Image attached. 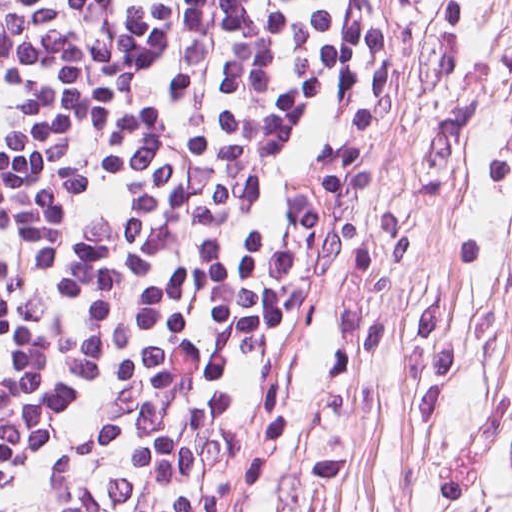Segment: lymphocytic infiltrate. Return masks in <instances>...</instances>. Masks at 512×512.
I'll list each match as a JSON object with an SVG mask.
<instances>
[{"label":"lymphocytic infiltrate","instance_id":"f902f5d3","mask_svg":"<svg viewBox=\"0 0 512 512\" xmlns=\"http://www.w3.org/2000/svg\"><path fill=\"white\" fill-rule=\"evenodd\" d=\"M401 8L0 0V512L226 511Z\"/></svg>","mask_w":512,"mask_h":512}]
</instances>
